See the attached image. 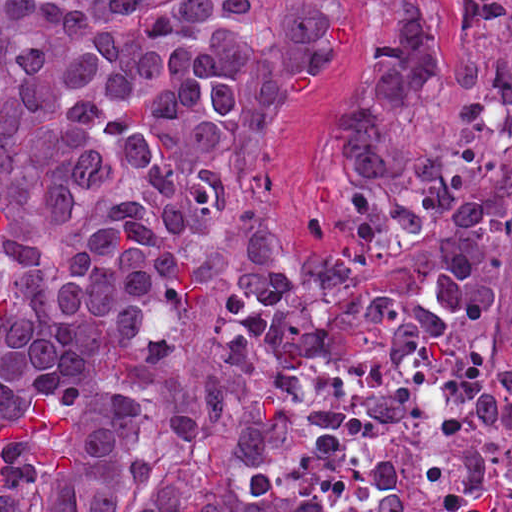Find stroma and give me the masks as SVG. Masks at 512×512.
Here are the masks:
<instances>
[{
    "label": "stroma",
    "mask_w": 512,
    "mask_h": 512,
    "mask_svg": "<svg viewBox=\"0 0 512 512\" xmlns=\"http://www.w3.org/2000/svg\"><path fill=\"white\" fill-rule=\"evenodd\" d=\"M371 17H348L331 47L307 78L264 167L257 195L247 210L196 233L193 240L224 243L222 273L208 286L168 301L160 319L172 326L188 358L220 360L218 317L231 287L240 238L258 235L271 248L315 251L348 239V217L328 167V141L340 128L360 89L369 55ZM498 45L487 33H468L444 0V43L440 58L426 68L406 102V122L426 151H452L484 161L497 174L511 226L512 146H497L463 133L455 118L458 84L447 73L455 57L492 60ZM148 203L141 195L106 199L81 227L68 233L29 222L0 197V217L42 240L78 242L117 209ZM512 356V320L501 357ZM229 376L241 388H260L273 405L277 443L282 442V392Z\"/></svg>",
    "instance_id": "1"
}]
</instances>
